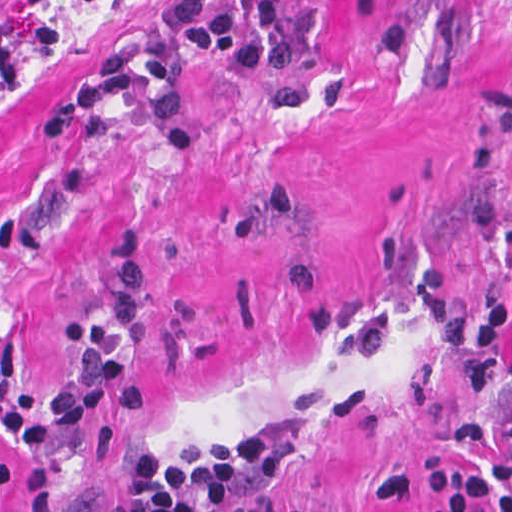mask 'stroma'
<instances>
[{
    "instance_id": "35a3bbf8",
    "label": "stroma",
    "mask_w": 512,
    "mask_h": 512,
    "mask_svg": "<svg viewBox=\"0 0 512 512\" xmlns=\"http://www.w3.org/2000/svg\"><path fill=\"white\" fill-rule=\"evenodd\" d=\"M165 12L0 0V512H136L194 426L240 434L329 512H425L373 483L467 461L455 430L512 405L427 323L435 296L512 312V0H298L288 79L244 87L183 59L193 150L135 101L107 109L104 140L33 144L92 63ZM121 232L146 247L149 406L17 457L1 355L18 348V386L55 383L63 324L108 306ZM484 475L477 511L512 498V470Z\"/></svg>"
}]
</instances>
